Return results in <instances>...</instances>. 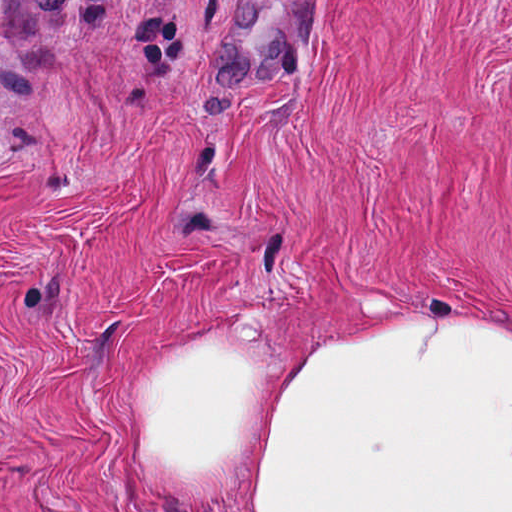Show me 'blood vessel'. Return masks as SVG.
I'll use <instances>...</instances> for the list:
<instances>
[{
    "mask_svg": "<svg viewBox=\"0 0 512 512\" xmlns=\"http://www.w3.org/2000/svg\"><path fill=\"white\" fill-rule=\"evenodd\" d=\"M306 24V1H236L214 44L210 77L266 83L290 66Z\"/></svg>",
    "mask_w": 512,
    "mask_h": 512,
    "instance_id": "blood-vessel-1",
    "label": "blood vessel"
}]
</instances>
